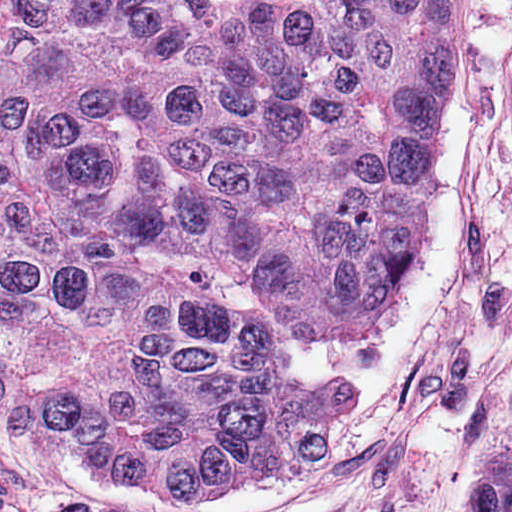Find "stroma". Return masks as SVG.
Listing matches in <instances>:
<instances>
[{"instance_id": "35a3bbf8", "label": "stroma", "mask_w": 512, "mask_h": 512, "mask_svg": "<svg viewBox=\"0 0 512 512\" xmlns=\"http://www.w3.org/2000/svg\"><path fill=\"white\" fill-rule=\"evenodd\" d=\"M437 160L393 312L277 343L290 381L365 392L339 443L234 503L161 506L73 455L0 374V512H464L512 430V0H449Z\"/></svg>"}]
</instances>
